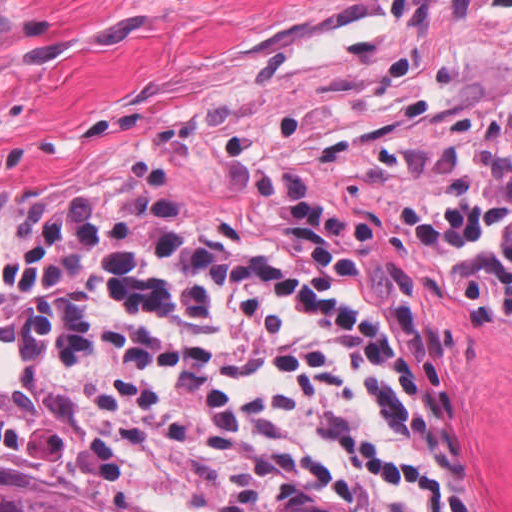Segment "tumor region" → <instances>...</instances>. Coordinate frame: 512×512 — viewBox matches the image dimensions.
I'll return each mask as SVG.
<instances>
[{
  "label": "tumor region",
  "instance_id": "1",
  "mask_svg": "<svg viewBox=\"0 0 512 512\" xmlns=\"http://www.w3.org/2000/svg\"><path fill=\"white\" fill-rule=\"evenodd\" d=\"M0 512H158L121 491L0 479Z\"/></svg>",
  "mask_w": 512,
  "mask_h": 512
}]
</instances>
